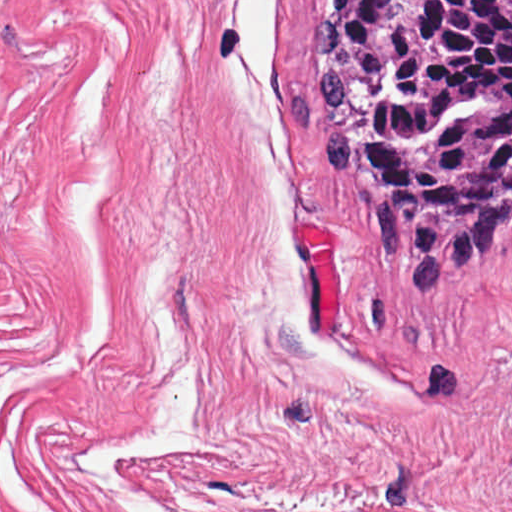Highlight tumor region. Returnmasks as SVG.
I'll return each instance as SVG.
<instances>
[{
    "label": "tumor region",
    "instance_id": "e687c5a6",
    "mask_svg": "<svg viewBox=\"0 0 512 512\" xmlns=\"http://www.w3.org/2000/svg\"><path fill=\"white\" fill-rule=\"evenodd\" d=\"M321 163L439 298L512 225V0H318Z\"/></svg>",
    "mask_w": 512,
    "mask_h": 512
}]
</instances>
